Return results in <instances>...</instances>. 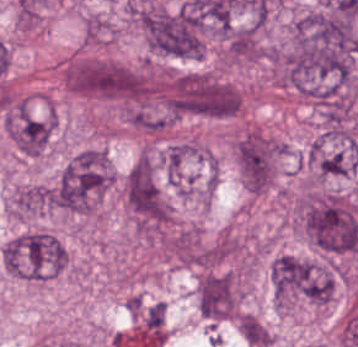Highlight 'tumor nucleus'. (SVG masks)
I'll list each match as a JSON object with an SVG mask.
<instances>
[{"label": "tumor nucleus", "instance_id": "2f306a5c", "mask_svg": "<svg viewBox=\"0 0 358 347\" xmlns=\"http://www.w3.org/2000/svg\"><path fill=\"white\" fill-rule=\"evenodd\" d=\"M148 48L182 58L205 49V21L188 1L159 5L139 13Z\"/></svg>", "mask_w": 358, "mask_h": 347}, {"label": "tumor nucleus", "instance_id": "8643909e", "mask_svg": "<svg viewBox=\"0 0 358 347\" xmlns=\"http://www.w3.org/2000/svg\"><path fill=\"white\" fill-rule=\"evenodd\" d=\"M114 176L108 150L88 147L66 162L54 186L52 201L70 212L90 213Z\"/></svg>", "mask_w": 358, "mask_h": 347}, {"label": "tumor nucleus", "instance_id": "5ab6c2c4", "mask_svg": "<svg viewBox=\"0 0 358 347\" xmlns=\"http://www.w3.org/2000/svg\"><path fill=\"white\" fill-rule=\"evenodd\" d=\"M274 297L280 309L326 304V265L298 254L282 251L270 262Z\"/></svg>", "mask_w": 358, "mask_h": 347}, {"label": "tumor nucleus", "instance_id": "2cbd58db", "mask_svg": "<svg viewBox=\"0 0 358 347\" xmlns=\"http://www.w3.org/2000/svg\"><path fill=\"white\" fill-rule=\"evenodd\" d=\"M4 268L14 275L40 281L67 263L60 242L48 231L33 229L10 238L1 250Z\"/></svg>", "mask_w": 358, "mask_h": 347}, {"label": "tumor nucleus", "instance_id": "3d1891a8", "mask_svg": "<svg viewBox=\"0 0 358 347\" xmlns=\"http://www.w3.org/2000/svg\"><path fill=\"white\" fill-rule=\"evenodd\" d=\"M63 80L79 95L126 98L132 73L126 65L114 60L79 59L67 63Z\"/></svg>", "mask_w": 358, "mask_h": 347}, {"label": "tumor nucleus", "instance_id": "2083b535", "mask_svg": "<svg viewBox=\"0 0 358 347\" xmlns=\"http://www.w3.org/2000/svg\"><path fill=\"white\" fill-rule=\"evenodd\" d=\"M285 145L256 129L238 135L235 149L243 182L248 188L265 189L275 178Z\"/></svg>", "mask_w": 358, "mask_h": 347}, {"label": "tumor nucleus", "instance_id": "8087334f", "mask_svg": "<svg viewBox=\"0 0 358 347\" xmlns=\"http://www.w3.org/2000/svg\"><path fill=\"white\" fill-rule=\"evenodd\" d=\"M124 201L134 212L162 218V194L151 153H141L123 177Z\"/></svg>", "mask_w": 358, "mask_h": 347}, {"label": "tumor nucleus", "instance_id": "c2bd9aea", "mask_svg": "<svg viewBox=\"0 0 358 347\" xmlns=\"http://www.w3.org/2000/svg\"><path fill=\"white\" fill-rule=\"evenodd\" d=\"M196 303L205 318L216 321L231 318L238 311L236 277L228 272L206 271L199 278Z\"/></svg>", "mask_w": 358, "mask_h": 347}, {"label": "tumor nucleus", "instance_id": "feef74b5", "mask_svg": "<svg viewBox=\"0 0 358 347\" xmlns=\"http://www.w3.org/2000/svg\"><path fill=\"white\" fill-rule=\"evenodd\" d=\"M358 159L352 137L320 135L311 145L310 162L320 175H345Z\"/></svg>", "mask_w": 358, "mask_h": 347}, {"label": "tumor nucleus", "instance_id": "3e47fb67", "mask_svg": "<svg viewBox=\"0 0 358 347\" xmlns=\"http://www.w3.org/2000/svg\"><path fill=\"white\" fill-rule=\"evenodd\" d=\"M56 124L55 113L17 111L8 122V133L25 154L45 149Z\"/></svg>", "mask_w": 358, "mask_h": 347}, {"label": "tumor nucleus", "instance_id": "f7901128", "mask_svg": "<svg viewBox=\"0 0 358 347\" xmlns=\"http://www.w3.org/2000/svg\"><path fill=\"white\" fill-rule=\"evenodd\" d=\"M53 188L42 184L20 186L13 199V212L19 215L42 213L52 208Z\"/></svg>", "mask_w": 358, "mask_h": 347}, {"label": "tumor nucleus", "instance_id": "268c6acd", "mask_svg": "<svg viewBox=\"0 0 358 347\" xmlns=\"http://www.w3.org/2000/svg\"><path fill=\"white\" fill-rule=\"evenodd\" d=\"M240 330L245 341L258 347H266L273 336L257 317L248 312L240 314Z\"/></svg>", "mask_w": 358, "mask_h": 347}, {"label": "tumor nucleus", "instance_id": "1edb0cf7", "mask_svg": "<svg viewBox=\"0 0 358 347\" xmlns=\"http://www.w3.org/2000/svg\"><path fill=\"white\" fill-rule=\"evenodd\" d=\"M164 303L152 302L141 313L143 334H163Z\"/></svg>", "mask_w": 358, "mask_h": 347}]
</instances>
